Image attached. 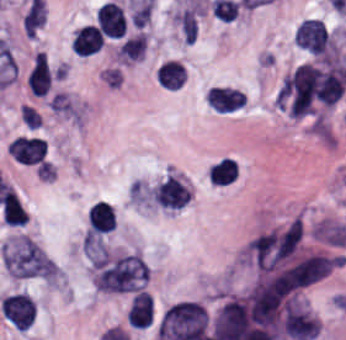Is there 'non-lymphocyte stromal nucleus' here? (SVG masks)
Masks as SVG:
<instances>
[{"label":"non-lymphocyte stromal nucleus","mask_w":346,"mask_h":340,"mask_svg":"<svg viewBox=\"0 0 346 340\" xmlns=\"http://www.w3.org/2000/svg\"><path fill=\"white\" fill-rule=\"evenodd\" d=\"M338 66L301 64L286 76L278 102L294 115H308Z\"/></svg>","instance_id":"1"},{"label":"non-lymphocyte stromal nucleus","mask_w":346,"mask_h":340,"mask_svg":"<svg viewBox=\"0 0 346 340\" xmlns=\"http://www.w3.org/2000/svg\"><path fill=\"white\" fill-rule=\"evenodd\" d=\"M149 267L139 252H125L97 266L94 287L102 292L120 293L141 288Z\"/></svg>","instance_id":"2"},{"label":"non-lymphocyte stromal nucleus","mask_w":346,"mask_h":340,"mask_svg":"<svg viewBox=\"0 0 346 340\" xmlns=\"http://www.w3.org/2000/svg\"><path fill=\"white\" fill-rule=\"evenodd\" d=\"M4 267L18 278H52L54 260L28 235L6 246Z\"/></svg>","instance_id":"3"},{"label":"non-lymphocyte stromal nucleus","mask_w":346,"mask_h":340,"mask_svg":"<svg viewBox=\"0 0 346 340\" xmlns=\"http://www.w3.org/2000/svg\"><path fill=\"white\" fill-rule=\"evenodd\" d=\"M151 194L162 208L182 209L189 201L191 189L169 175L152 189Z\"/></svg>","instance_id":"4"},{"label":"non-lymphocyte stromal nucleus","mask_w":346,"mask_h":340,"mask_svg":"<svg viewBox=\"0 0 346 340\" xmlns=\"http://www.w3.org/2000/svg\"><path fill=\"white\" fill-rule=\"evenodd\" d=\"M147 43V36L143 32L123 41L117 51V56L123 61L140 60Z\"/></svg>","instance_id":"5"},{"label":"non-lymphocyte stromal nucleus","mask_w":346,"mask_h":340,"mask_svg":"<svg viewBox=\"0 0 346 340\" xmlns=\"http://www.w3.org/2000/svg\"><path fill=\"white\" fill-rule=\"evenodd\" d=\"M183 39L192 44L198 36V19L193 8H186L175 14Z\"/></svg>","instance_id":"6"}]
</instances>
